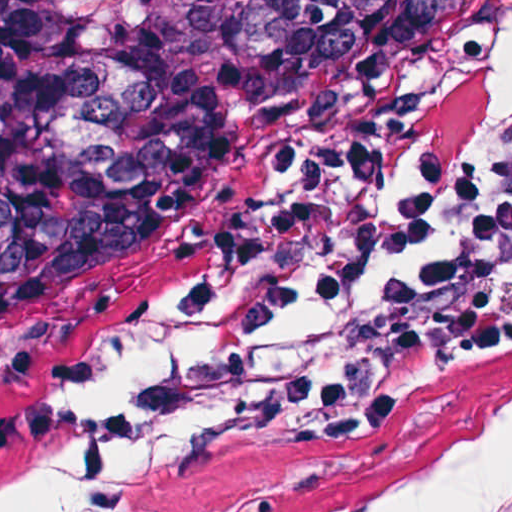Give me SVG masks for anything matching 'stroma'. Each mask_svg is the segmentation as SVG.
Masks as SVG:
<instances>
[{
	"label": "stroma",
	"mask_w": 512,
	"mask_h": 512,
	"mask_svg": "<svg viewBox=\"0 0 512 512\" xmlns=\"http://www.w3.org/2000/svg\"><path fill=\"white\" fill-rule=\"evenodd\" d=\"M511 47L512 0H497L452 73L408 126L334 161L384 154L379 191L387 200L409 188L414 177L396 179L387 160L424 130L458 118L487 89ZM201 263L112 339L0 401V410L38 399L98 408L135 404L151 380L200 343L204 321L174 312L168 295ZM278 345L377 360L384 392L370 428L342 447H309L218 431L212 410L201 412L142 454L123 512H313L439 463L512 418V354L488 368L407 366L388 355L381 334L334 317L306 319ZM42 461H61L70 477L66 512L82 480L76 457L0 454V475Z\"/></svg>",
	"instance_id": "obj_1"
}]
</instances>
